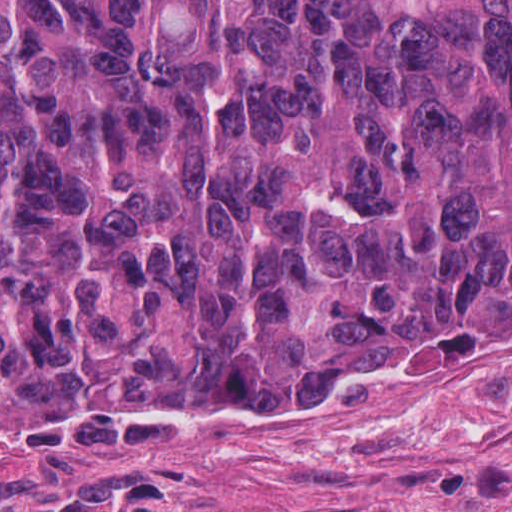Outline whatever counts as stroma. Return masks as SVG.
Listing matches in <instances>:
<instances>
[{
    "label": "stroma",
    "mask_w": 512,
    "mask_h": 512,
    "mask_svg": "<svg viewBox=\"0 0 512 512\" xmlns=\"http://www.w3.org/2000/svg\"><path fill=\"white\" fill-rule=\"evenodd\" d=\"M0 512H512V330L245 397L0 416Z\"/></svg>",
    "instance_id": "35a3bbf8"
}]
</instances>
